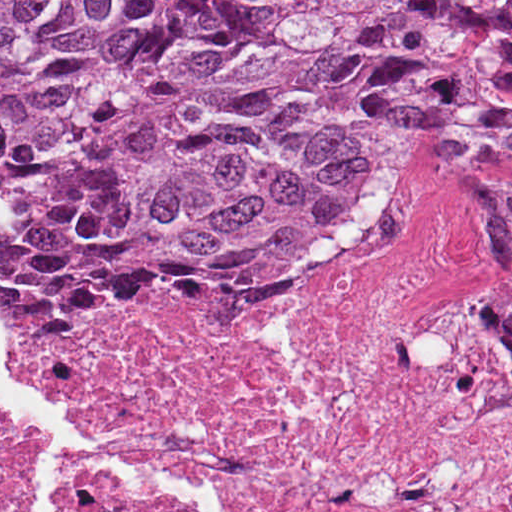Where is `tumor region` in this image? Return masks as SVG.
Returning a JSON list of instances; mask_svg holds the SVG:
<instances>
[{
	"instance_id": "1",
	"label": "tumor region",
	"mask_w": 512,
	"mask_h": 512,
	"mask_svg": "<svg viewBox=\"0 0 512 512\" xmlns=\"http://www.w3.org/2000/svg\"><path fill=\"white\" fill-rule=\"evenodd\" d=\"M455 120L512 123V0H0V299L319 289Z\"/></svg>"
}]
</instances>
